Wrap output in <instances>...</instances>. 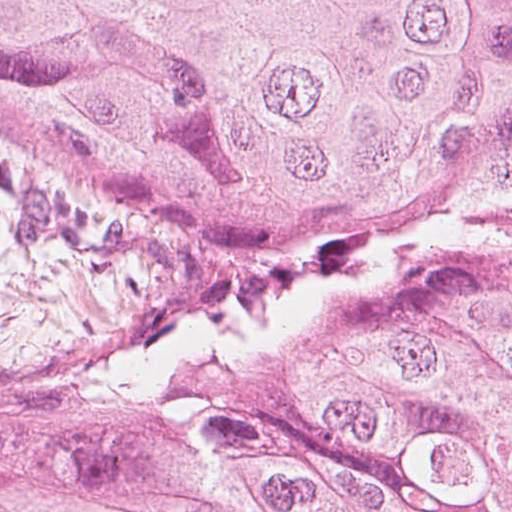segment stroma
<instances>
[{
    "label": "stroma",
    "mask_w": 512,
    "mask_h": 512,
    "mask_svg": "<svg viewBox=\"0 0 512 512\" xmlns=\"http://www.w3.org/2000/svg\"><path fill=\"white\" fill-rule=\"evenodd\" d=\"M306 259L73 196L0 141V395L205 284Z\"/></svg>",
    "instance_id": "stroma-1"
}]
</instances>
